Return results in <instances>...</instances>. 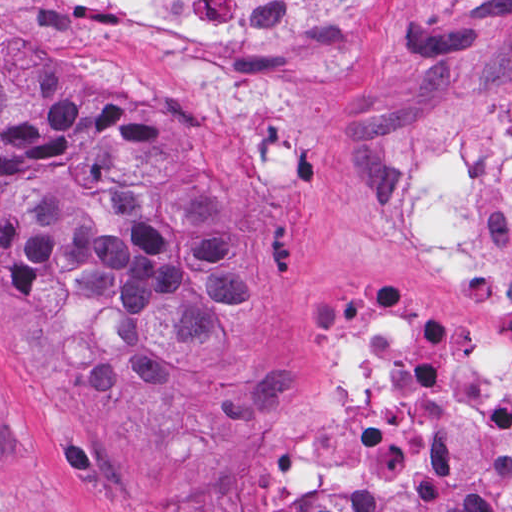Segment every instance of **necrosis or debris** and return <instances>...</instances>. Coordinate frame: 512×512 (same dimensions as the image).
<instances>
[{"label": "necrosis or debris", "mask_w": 512, "mask_h": 512, "mask_svg": "<svg viewBox=\"0 0 512 512\" xmlns=\"http://www.w3.org/2000/svg\"><path fill=\"white\" fill-rule=\"evenodd\" d=\"M199 89L206 118L266 124L380 39L382 0H108ZM398 247L484 320L512 321V111L491 142L433 139L401 186ZM320 439L261 447L250 477L512 488V361L443 347L406 305L347 303L323 328Z\"/></svg>", "instance_id": "obj_1"}]
</instances>
